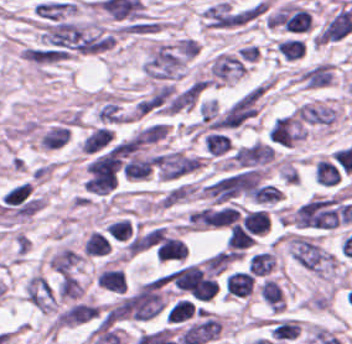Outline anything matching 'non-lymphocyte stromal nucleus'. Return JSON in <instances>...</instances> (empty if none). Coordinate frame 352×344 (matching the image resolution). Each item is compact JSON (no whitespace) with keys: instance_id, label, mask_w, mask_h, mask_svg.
Segmentation results:
<instances>
[{"instance_id":"obj_1","label":"non-lymphocyte stromal nucleus","mask_w":352,"mask_h":344,"mask_svg":"<svg viewBox=\"0 0 352 344\" xmlns=\"http://www.w3.org/2000/svg\"><path fill=\"white\" fill-rule=\"evenodd\" d=\"M274 151L264 143L251 142L235 147L225 160L226 168L265 172Z\"/></svg>"},{"instance_id":"obj_2","label":"non-lymphocyte stromal nucleus","mask_w":352,"mask_h":344,"mask_svg":"<svg viewBox=\"0 0 352 344\" xmlns=\"http://www.w3.org/2000/svg\"><path fill=\"white\" fill-rule=\"evenodd\" d=\"M23 298L43 314H54L58 306L57 290L39 272H32L23 282Z\"/></svg>"}]
</instances>
